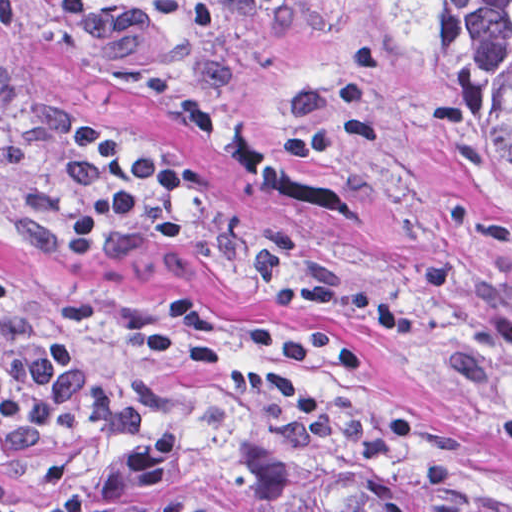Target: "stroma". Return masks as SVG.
<instances>
[{
	"label": "stroma",
	"instance_id": "1",
	"mask_svg": "<svg viewBox=\"0 0 512 512\" xmlns=\"http://www.w3.org/2000/svg\"><path fill=\"white\" fill-rule=\"evenodd\" d=\"M61 0H0V278L27 318L69 300L103 311L82 337L96 376L137 367L145 324L202 298L216 344L290 325L356 341L371 366L331 372L338 399L288 424L203 379L166 377L133 443L64 433L0 499L83 486L149 437H188L272 465L306 494L347 482L422 512H512V173L464 107L405 0H117L67 28ZM130 152L202 168L180 245L138 225L62 259L57 234L91 173L72 121ZM8 338L0 327V368ZM258 363V362H257Z\"/></svg>",
	"mask_w": 512,
	"mask_h": 512
}]
</instances>
